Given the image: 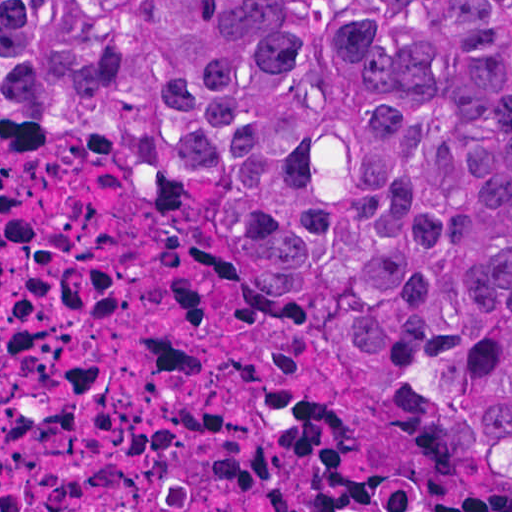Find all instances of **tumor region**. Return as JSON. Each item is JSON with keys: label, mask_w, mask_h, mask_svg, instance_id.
I'll return each instance as SVG.
<instances>
[{"label": "tumor region", "mask_w": 512, "mask_h": 512, "mask_svg": "<svg viewBox=\"0 0 512 512\" xmlns=\"http://www.w3.org/2000/svg\"><path fill=\"white\" fill-rule=\"evenodd\" d=\"M183 181L336 342L472 392L512 460V0H0V126Z\"/></svg>", "instance_id": "tumor-region-1"}]
</instances>
